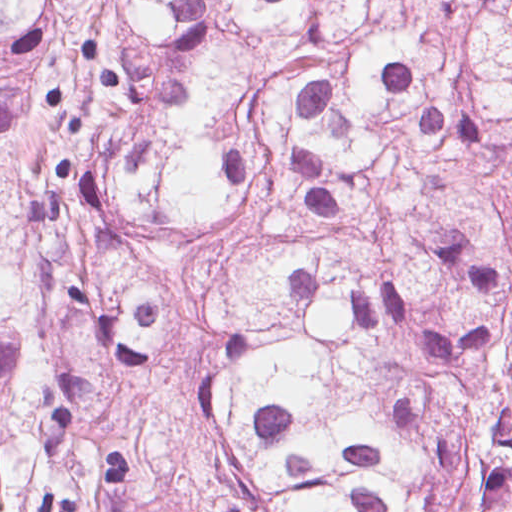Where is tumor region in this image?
Listing matches in <instances>:
<instances>
[{"label": "tumor region", "mask_w": 512, "mask_h": 512, "mask_svg": "<svg viewBox=\"0 0 512 512\" xmlns=\"http://www.w3.org/2000/svg\"><path fill=\"white\" fill-rule=\"evenodd\" d=\"M0 512H512V0H0Z\"/></svg>", "instance_id": "obj_1"}]
</instances>
